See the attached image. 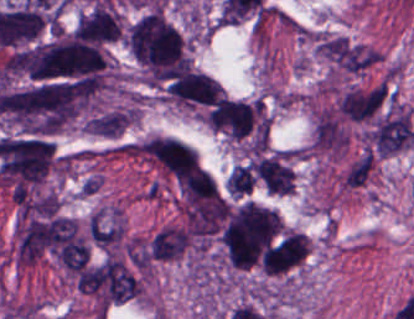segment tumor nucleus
<instances>
[{"label":"tumor nucleus","instance_id":"obj_1","mask_svg":"<svg viewBox=\"0 0 414 319\" xmlns=\"http://www.w3.org/2000/svg\"><path fill=\"white\" fill-rule=\"evenodd\" d=\"M207 123L247 148L265 150L268 145V111L257 97L223 96L207 112Z\"/></svg>","mask_w":414,"mask_h":319},{"label":"tumor nucleus","instance_id":"obj_2","mask_svg":"<svg viewBox=\"0 0 414 319\" xmlns=\"http://www.w3.org/2000/svg\"><path fill=\"white\" fill-rule=\"evenodd\" d=\"M250 167L256 184L271 194H290L295 187L291 152L268 151L253 154Z\"/></svg>","mask_w":414,"mask_h":319},{"label":"tumor nucleus","instance_id":"obj_3","mask_svg":"<svg viewBox=\"0 0 414 319\" xmlns=\"http://www.w3.org/2000/svg\"><path fill=\"white\" fill-rule=\"evenodd\" d=\"M309 251L310 237L299 230L283 242L273 273L289 272L305 261Z\"/></svg>","mask_w":414,"mask_h":319},{"label":"tumor nucleus","instance_id":"obj_4","mask_svg":"<svg viewBox=\"0 0 414 319\" xmlns=\"http://www.w3.org/2000/svg\"><path fill=\"white\" fill-rule=\"evenodd\" d=\"M254 181L251 167L248 164L237 165L232 168L226 183L227 193L235 196L249 194Z\"/></svg>","mask_w":414,"mask_h":319}]
</instances>
